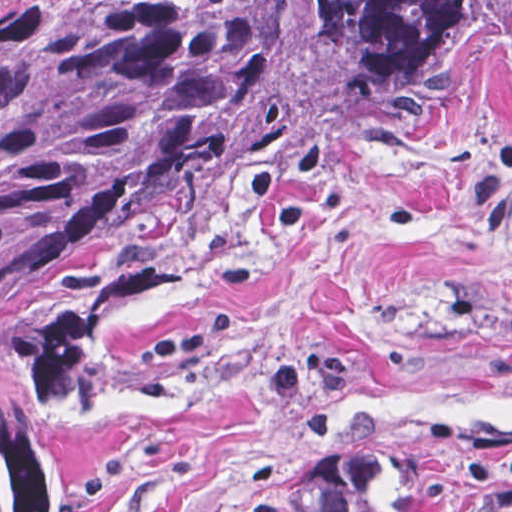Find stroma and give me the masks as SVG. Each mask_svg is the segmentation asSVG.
Listing matches in <instances>:
<instances>
[{
    "label": "stroma",
    "instance_id": "obj_1",
    "mask_svg": "<svg viewBox=\"0 0 512 512\" xmlns=\"http://www.w3.org/2000/svg\"><path fill=\"white\" fill-rule=\"evenodd\" d=\"M412 439L512 440V50L356 133L92 391L70 512H331Z\"/></svg>",
    "mask_w": 512,
    "mask_h": 512
}]
</instances>
